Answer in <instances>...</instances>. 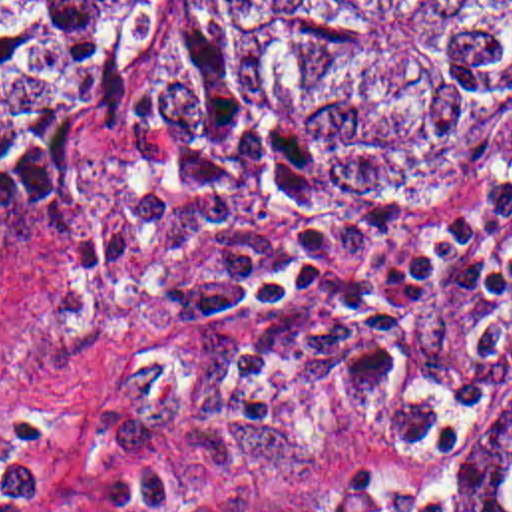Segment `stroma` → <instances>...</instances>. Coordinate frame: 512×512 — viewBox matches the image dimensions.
I'll return each mask as SVG.
<instances>
[{
    "mask_svg": "<svg viewBox=\"0 0 512 512\" xmlns=\"http://www.w3.org/2000/svg\"><path fill=\"white\" fill-rule=\"evenodd\" d=\"M168 2H146L89 219L0 227V460L35 454V512H457L512 402V199L431 271L407 386L347 388L345 324L322 299L196 318L246 235L393 215L399 229L343 273L399 263L512 171V99L391 201L331 197L266 99L216 105L160 167L134 99Z\"/></svg>",
    "mask_w": 512,
    "mask_h": 512,
    "instance_id": "stroma-1",
    "label": "stroma"
}]
</instances>
